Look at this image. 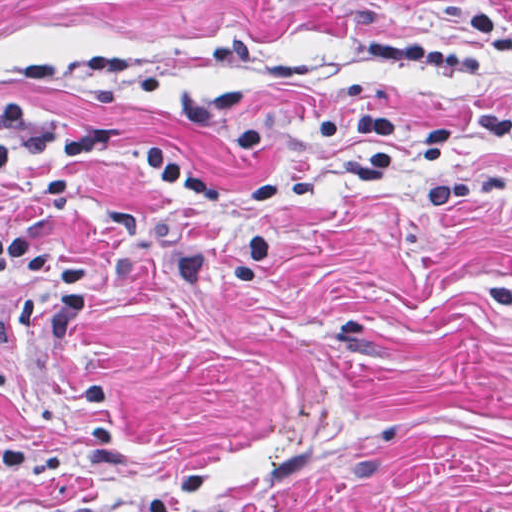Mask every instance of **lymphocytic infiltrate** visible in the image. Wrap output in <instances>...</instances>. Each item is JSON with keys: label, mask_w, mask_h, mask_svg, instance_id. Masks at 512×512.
I'll return each instance as SVG.
<instances>
[{"label": "lymphocytic infiltrate", "mask_w": 512, "mask_h": 512, "mask_svg": "<svg viewBox=\"0 0 512 512\" xmlns=\"http://www.w3.org/2000/svg\"><path fill=\"white\" fill-rule=\"evenodd\" d=\"M377 66L392 71H419L450 79L481 74L477 60L462 52L428 50L406 45H373L364 50ZM355 128L364 140L356 156L357 170L372 176L393 166L392 141L410 144L419 166L446 163L458 135L455 119L426 124L408 122L388 110L359 112ZM126 140L107 131H79L41 122L0 101V177L21 164H79L97 154H118ZM139 164L165 191L187 205L235 227L241 244L228 252H180L169 268L175 281L190 287H246L259 281L269 265V240L261 226L229 206L271 204L317 197L321 180L307 176H264L236 185L203 166L187 163L158 149L139 153Z\"/></svg>", "instance_id": "1"}]
</instances>
